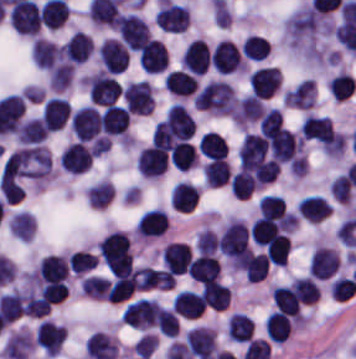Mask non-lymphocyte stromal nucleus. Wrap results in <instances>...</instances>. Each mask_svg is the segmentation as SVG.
Wrapping results in <instances>:
<instances>
[{
  "instance_id": "obj_15",
  "label": "non-lymphocyte stromal nucleus",
  "mask_w": 356,
  "mask_h": 359,
  "mask_svg": "<svg viewBox=\"0 0 356 359\" xmlns=\"http://www.w3.org/2000/svg\"><path fill=\"white\" fill-rule=\"evenodd\" d=\"M186 271L195 281H209L218 278L219 264L217 257L208 251L199 254L190 260Z\"/></svg>"
},
{
  "instance_id": "obj_5",
  "label": "non-lymphocyte stromal nucleus",
  "mask_w": 356,
  "mask_h": 359,
  "mask_svg": "<svg viewBox=\"0 0 356 359\" xmlns=\"http://www.w3.org/2000/svg\"><path fill=\"white\" fill-rule=\"evenodd\" d=\"M122 99L130 113L149 114L152 111V90L146 80L126 84L123 87Z\"/></svg>"
},
{
  "instance_id": "obj_3",
  "label": "non-lymphocyte stromal nucleus",
  "mask_w": 356,
  "mask_h": 359,
  "mask_svg": "<svg viewBox=\"0 0 356 359\" xmlns=\"http://www.w3.org/2000/svg\"><path fill=\"white\" fill-rule=\"evenodd\" d=\"M158 313L155 298L140 297L126 305L120 319L122 323L147 331L158 321Z\"/></svg>"
},
{
  "instance_id": "obj_9",
  "label": "non-lymphocyte stromal nucleus",
  "mask_w": 356,
  "mask_h": 359,
  "mask_svg": "<svg viewBox=\"0 0 356 359\" xmlns=\"http://www.w3.org/2000/svg\"><path fill=\"white\" fill-rule=\"evenodd\" d=\"M249 89L259 96H272L281 85L280 70L272 66H259L248 76Z\"/></svg>"
},
{
  "instance_id": "obj_23",
  "label": "non-lymphocyte stromal nucleus",
  "mask_w": 356,
  "mask_h": 359,
  "mask_svg": "<svg viewBox=\"0 0 356 359\" xmlns=\"http://www.w3.org/2000/svg\"><path fill=\"white\" fill-rule=\"evenodd\" d=\"M8 227L12 236L29 241L35 232V220L29 212L17 210L11 216Z\"/></svg>"
},
{
  "instance_id": "obj_19",
  "label": "non-lymphocyte stromal nucleus",
  "mask_w": 356,
  "mask_h": 359,
  "mask_svg": "<svg viewBox=\"0 0 356 359\" xmlns=\"http://www.w3.org/2000/svg\"><path fill=\"white\" fill-rule=\"evenodd\" d=\"M332 204L316 194L302 197L296 206L299 216L307 221H321L330 212Z\"/></svg>"
},
{
  "instance_id": "obj_8",
  "label": "non-lymphocyte stromal nucleus",
  "mask_w": 356,
  "mask_h": 359,
  "mask_svg": "<svg viewBox=\"0 0 356 359\" xmlns=\"http://www.w3.org/2000/svg\"><path fill=\"white\" fill-rule=\"evenodd\" d=\"M339 257L331 246L316 245L309 260V273L320 280H327L337 271Z\"/></svg>"
},
{
  "instance_id": "obj_11",
  "label": "non-lymphocyte stromal nucleus",
  "mask_w": 356,
  "mask_h": 359,
  "mask_svg": "<svg viewBox=\"0 0 356 359\" xmlns=\"http://www.w3.org/2000/svg\"><path fill=\"white\" fill-rule=\"evenodd\" d=\"M167 61V49L162 40L150 36L140 47L138 62L148 72H162Z\"/></svg>"
},
{
  "instance_id": "obj_12",
  "label": "non-lymphocyte stromal nucleus",
  "mask_w": 356,
  "mask_h": 359,
  "mask_svg": "<svg viewBox=\"0 0 356 359\" xmlns=\"http://www.w3.org/2000/svg\"><path fill=\"white\" fill-rule=\"evenodd\" d=\"M99 61L104 71L121 72L127 65L128 50L113 38H106L99 45Z\"/></svg>"
},
{
  "instance_id": "obj_22",
  "label": "non-lymphocyte stromal nucleus",
  "mask_w": 356,
  "mask_h": 359,
  "mask_svg": "<svg viewBox=\"0 0 356 359\" xmlns=\"http://www.w3.org/2000/svg\"><path fill=\"white\" fill-rule=\"evenodd\" d=\"M254 318L247 313L234 312L228 322V334L233 340L247 342L254 333Z\"/></svg>"
},
{
  "instance_id": "obj_13",
  "label": "non-lymphocyte stromal nucleus",
  "mask_w": 356,
  "mask_h": 359,
  "mask_svg": "<svg viewBox=\"0 0 356 359\" xmlns=\"http://www.w3.org/2000/svg\"><path fill=\"white\" fill-rule=\"evenodd\" d=\"M167 165V153L154 144L140 149L136 162L138 173L155 178L167 168Z\"/></svg>"
},
{
  "instance_id": "obj_31",
  "label": "non-lymphocyte stromal nucleus",
  "mask_w": 356,
  "mask_h": 359,
  "mask_svg": "<svg viewBox=\"0 0 356 359\" xmlns=\"http://www.w3.org/2000/svg\"><path fill=\"white\" fill-rule=\"evenodd\" d=\"M328 189L337 203H345L351 199L352 185L342 172L328 183Z\"/></svg>"
},
{
  "instance_id": "obj_17",
  "label": "non-lymphocyte stromal nucleus",
  "mask_w": 356,
  "mask_h": 359,
  "mask_svg": "<svg viewBox=\"0 0 356 359\" xmlns=\"http://www.w3.org/2000/svg\"><path fill=\"white\" fill-rule=\"evenodd\" d=\"M198 199V188L187 180H179L171 189L172 208L181 213H190Z\"/></svg>"
},
{
  "instance_id": "obj_20",
  "label": "non-lymphocyte stromal nucleus",
  "mask_w": 356,
  "mask_h": 359,
  "mask_svg": "<svg viewBox=\"0 0 356 359\" xmlns=\"http://www.w3.org/2000/svg\"><path fill=\"white\" fill-rule=\"evenodd\" d=\"M163 82L172 94L179 97H188L198 87L196 77L184 70H171Z\"/></svg>"
},
{
  "instance_id": "obj_18",
  "label": "non-lymphocyte stromal nucleus",
  "mask_w": 356,
  "mask_h": 359,
  "mask_svg": "<svg viewBox=\"0 0 356 359\" xmlns=\"http://www.w3.org/2000/svg\"><path fill=\"white\" fill-rule=\"evenodd\" d=\"M173 305L184 318H196L206 307L200 291L189 289H182L174 295Z\"/></svg>"
},
{
  "instance_id": "obj_27",
  "label": "non-lymphocyte stromal nucleus",
  "mask_w": 356,
  "mask_h": 359,
  "mask_svg": "<svg viewBox=\"0 0 356 359\" xmlns=\"http://www.w3.org/2000/svg\"><path fill=\"white\" fill-rule=\"evenodd\" d=\"M270 41L261 34H248L241 45V53L250 60H264Z\"/></svg>"
},
{
  "instance_id": "obj_25",
  "label": "non-lymphocyte stromal nucleus",
  "mask_w": 356,
  "mask_h": 359,
  "mask_svg": "<svg viewBox=\"0 0 356 359\" xmlns=\"http://www.w3.org/2000/svg\"><path fill=\"white\" fill-rule=\"evenodd\" d=\"M80 290L84 295L106 299L110 297V280L101 275L90 274L81 277Z\"/></svg>"
},
{
  "instance_id": "obj_26",
  "label": "non-lymphocyte stromal nucleus",
  "mask_w": 356,
  "mask_h": 359,
  "mask_svg": "<svg viewBox=\"0 0 356 359\" xmlns=\"http://www.w3.org/2000/svg\"><path fill=\"white\" fill-rule=\"evenodd\" d=\"M231 167L226 158H213L204 166V178L209 185H223L230 179Z\"/></svg>"
},
{
  "instance_id": "obj_29",
  "label": "non-lymphocyte stromal nucleus",
  "mask_w": 356,
  "mask_h": 359,
  "mask_svg": "<svg viewBox=\"0 0 356 359\" xmlns=\"http://www.w3.org/2000/svg\"><path fill=\"white\" fill-rule=\"evenodd\" d=\"M195 158L193 144L187 141L178 143L169 153V160L177 169H190L194 165Z\"/></svg>"
},
{
  "instance_id": "obj_16",
  "label": "non-lymphocyte stromal nucleus",
  "mask_w": 356,
  "mask_h": 359,
  "mask_svg": "<svg viewBox=\"0 0 356 359\" xmlns=\"http://www.w3.org/2000/svg\"><path fill=\"white\" fill-rule=\"evenodd\" d=\"M59 56L60 49L50 40L34 38L30 43L31 62L46 71L57 62Z\"/></svg>"
},
{
  "instance_id": "obj_7",
  "label": "non-lymphocyte stromal nucleus",
  "mask_w": 356,
  "mask_h": 359,
  "mask_svg": "<svg viewBox=\"0 0 356 359\" xmlns=\"http://www.w3.org/2000/svg\"><path fill=\"white\" fill-rule=\"evenodd\" d=\"M69 270L64 256L48 254L39 260L35 269V278L42 284L66 282Z\"/></svg>"
},
{
  "instance_id": "obj_14",
  "label": "non-lymphocyte stromal nucleus",
  "mask_w": 356,
  "mask_h": 359,
  "mask_svg": "<svg viewBox=\"0 0 356 359\" xmlns=\"http://www.w3.org/2000/svg\"><path fill=\"white\" fill-rule=\"evenodd\" d=\"M210 49L204 39L194 38L186 47L181 66L187 70L202 74L208 70Z\"/></svg>"
},
{
  "instance_id": "obj_28",
  "label": "non-lymphocyte stromal nucleus",
  "mask_w": 356,
  "mask_h": 359,
  "mask_svg": "<svg viewBox=\"0 0 356 359\" xmlns=\"http://www.w3.org/2000/svg\"><path fill=\"white\" fill-rule=\"evenodd\" d=\"M113 189L110 182L101 179L84 189V196L90 206L103 208L111 199Z\"/></svg>"
},
{
  "instance_id": "obj_10",
  "label": "non-lymphocyte stromal nucleus",
  "mask_w": 356,
  "mask_h": 359,
  "mask_svg": "<svg viewBox=\"0 0 356 359\" xmlns=\"http://www.w3.org/2000/svg\"><path fill=\"white\" fill-rule=\"evenodd\" d=\"M65 330L64 323L44 318L36 328L35 340L44 353L56 355L64 342Z\"/></svg>"
},
{
  "instance_id": "obj_24",
  "label": "non-lymphocyte stromal nucleus",
  "mask_w": 356,
  "mask_h": 359,
  "mask_svg": "<svg viewBox=\"0 0 356 359\" xmlns=\"http://www.w3.org/2000/svg\"><path fill=\"white\" fill-rule=\"evenodd\" d=\"M198 146L200 153L209 159L226 157L228 151L224 137L214 131L200 134Z\"/></svg>"
},
{
  "instance_id": "obj_30",
  "label": "non-lymphocyte stromal nucleus",
  "mask_w": 356,
  "mask_h": 359,
  "mask_svg": "<svg viewBox=\"0 0 356 359\" xmlns=\"http://www.w3.org/2000/svg\"><path fill=\"white\" fill-rule=\"evenodd\" d=\"M286 209L285 200L281 195L265 193L258 203L260 216L281 217Z\"/></svg>"
},
{
  "instance_id": "obj_2",
  "label": "non-lymphocyte stromal nucleus",
  "mask_w": 356,
  "mask_h": 359,
  "mask_svg": "<svg viewBox=\"0 0 356 359\" xmlns=\"http://www.w3.org/2000/svg\"><path fill=\"white\" fill-rule=\"evenodd\" d=\"M86 94L89 103L108 105L121 92V86L114 74L98 70L86 76Z\"/></svg>"
},
{
  "instance_id": "obj_21",
  "label": "non-lymphocyte stromal nucleus",
  "mask_w": 356,
  "mask_h": 359,
  "mask_svg": "<svg viewBox=\"0 0 356 359\" xmlns=\"http://www.w3.org/2000/svg\"><path fill=\"white\" fill-rule=\"evenodd\" d=\"M92 53V38L90 34L76 30L66 41L64 56L71 63H81Z\"/></svg>"
},
{
  "instance_id": "obj_32",
  "label": "non-lymphocyte stromal nucleus",
  "mask_w": 356,
  "mask_h": 359,
  "mask_svg": "<svg viewBox=\"0 0 356 359\" xmlns=\"http://www.w3.org/2000/svg\"><path fill=\"white\" fill-rule=\"evenodd\" d=\"M157 328L164 334L177 336L179 319L173 308L159 307Z\"/></svg>"
},
{
  "instance_id": "obj_1",
  "label": "non-lymphocyte stromal nucleus",
  "mask_w": 356,
  "mask_h": 359,
  "mask_svg": "<svg viewBox=\"0 0 356 359\" xmlns=\"http://www.w3.org/2000/svg\"><path fill=\"white\" fill-rule=\"evenodd\" d=\"M19 175L43 183L52 173L51 155L47 146H22L15 149Z\"/></svg>"
},
{
  "instance_id": "obj_4",
  "label": "non-lymphocyte stromal nucleus",
  "mask_w": 356,
  "mask_h": 359,
  "mask_svg": "<svg viewBox=\"0 0 356 359\" xmlns=\"http://www.w3.org/2000/svg\"><path fill=\"white\" fill-rule=\"evenodd\" d=\"M70 126L77 138L90 141L101 132L100 112L96 106L84 105L71 115Z\"/></svg>"
},
{
  "instance_id": "obj_6",
  "label": "non-lymphocyte stromal nucleus",
  "mask_w": 356,
  "mask_h": 359,
  "mask_svg": "<svg viewBox=\"0 0 356 359\" xmlns=\"http://www.w3.org/2000/svg\"><path fill=\"white\" fill-rule=\"evenodd\" d=\"M210 62L217 72L230 73L242 70L244 63L237 45L222 39L210 52Z\"/></svg>"
}]
</instances>
